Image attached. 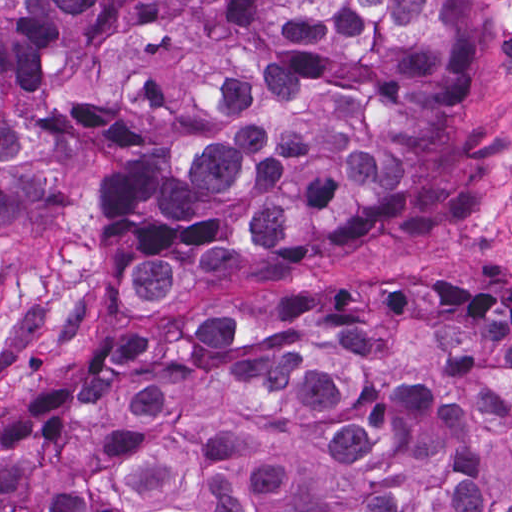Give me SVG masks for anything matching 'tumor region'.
<instances>
[{"mask_svg":"<svg viewBox=\"0 0 512 512\" xmlns=\"http://www.w3.org/2000/svg\"><path fill=\"white\" fill-rule=\"evenodd\" d=\"M472 0H0V225L91 200L125 295L476 202ZM0 512H512V290L292 276L49 378Z\"/></svg>","mask_w":512,"mask_h":512,"instance_id":"tumor-region-1","label":"tumor region"}]
</instances>
